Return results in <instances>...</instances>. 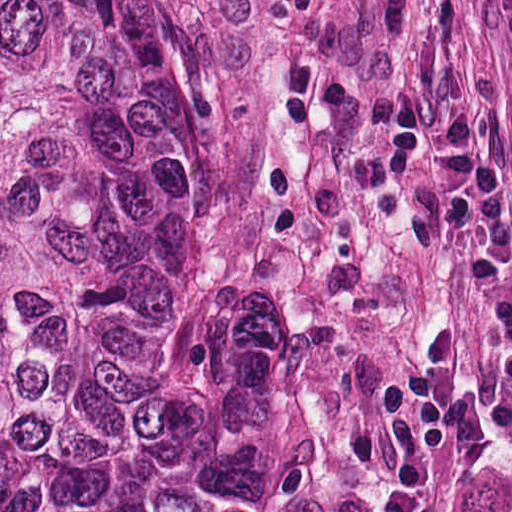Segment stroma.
I'll return each instance as SVG.
<instances>
[{"label":"stroma","instance_id":"1","mask_svg":"<svg viewBox=\"0 0 512 512\" xmlns=\"http://www.w3.org/2000/svg\"><path fill=\"white\" fill-rule=\"evenodd\" d=\"M204 259L278 289L356 360L403 427L426 512H512V449L429 450L382 389L429 308L457 331L458 387L480 406L502 364L469 288L430 159L384 161L392 94L475 118L512 211V0H189ZM512 281V266H511Z\"/></svg>","mask_w":512,"mask_h":512}]
</instances>
